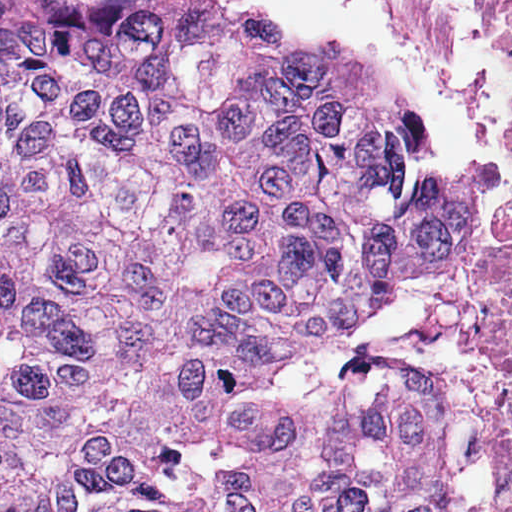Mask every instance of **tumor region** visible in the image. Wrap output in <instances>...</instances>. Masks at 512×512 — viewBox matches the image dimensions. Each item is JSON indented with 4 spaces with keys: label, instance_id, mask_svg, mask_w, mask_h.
Returning <instances> with one entry per match:
<instances>
[{
    "label": "tumor region",
    "instance_id": "1",
    "mask_svg": "<svg viewBox=\"0 0 512 512\" xmlns=\"http://www.w3.org/2000/svg\"><path fill=\"white\" fill-rule=\"evenodd\" d=\"M405 140L272 29L0 0V512H457L440 392L354 341L504 187Z\"/></svg>",
    "mask_w": 512,
    "mask_h": 512
}]
</instances>
